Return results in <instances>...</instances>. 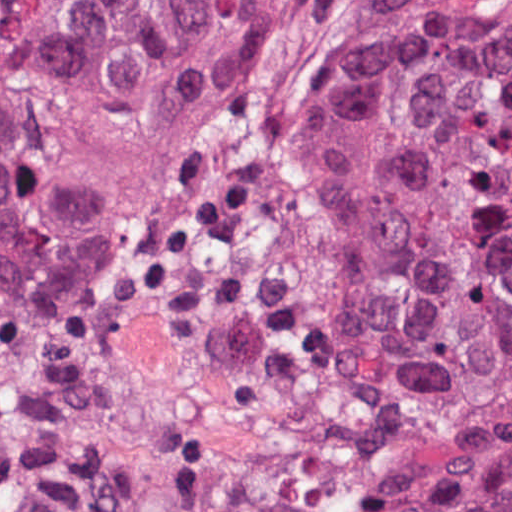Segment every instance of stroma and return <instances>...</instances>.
Masks as SVG:
<instances>
[{
  "mask_svg": "<svg viewBox=\"0 0 512 512\" xmlns=\"http://www.w3.org/2000/svg\"><path fill=\"white\" fill-rule=\"evenodd\" d=\"M0 1H378L399 22L458 18L512 32V0H0ZM74 320L67 316H48Z\"/></svg>",
  "mask_w": 512,
  "mask_h": 512,
  "instance_id": "35a3bbf8",
  "label": "stroma"
}]
</instances>
